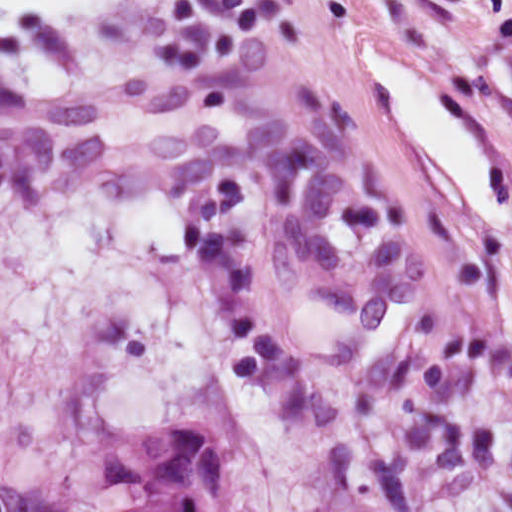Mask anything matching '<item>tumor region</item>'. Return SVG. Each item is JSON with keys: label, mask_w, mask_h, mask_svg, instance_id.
Masks as SVG:
<instances>
[{"label": "tumor region", "mask_w": 512, "mask_h": 512, "mask_svg": "<svg viewBox=\"0 0 512 512\" xmlns=\"http://www.w3.org/2000/svg\"><path fill=\"white\" fill-rule=\"evenodd\" d=\"M97 471L116 487L146 490L120 512H256L223 441L202 423L153 422L103 453Z\"/></svg>", "instance_id": "1"}]
</instances>
